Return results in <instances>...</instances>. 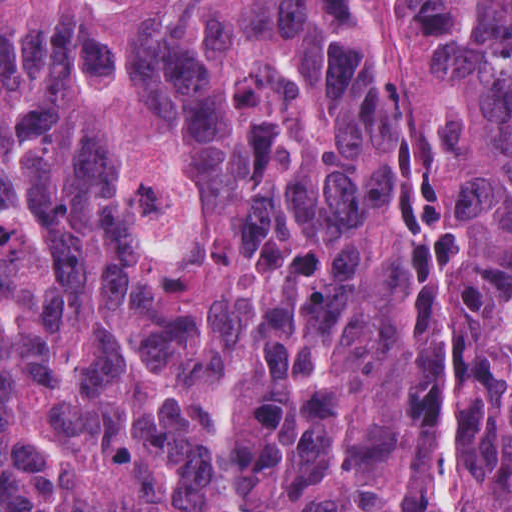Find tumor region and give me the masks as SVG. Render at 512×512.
<instances>
[{
    "label": "tumor region",
    "mask_w": 512,
    "mask_h": 512,
    "mask_svg": "<svg viewBox=\"0 0 512 512\" xmlns=\"http://www.w3.org/2000/svg\"><path fill=\"white\" fill-rule=\"evenodd\" d=\"M1 0V512H512V0Z\"/></svg>",
    "instance_id": "e687c5a6"
}]
</instances>
